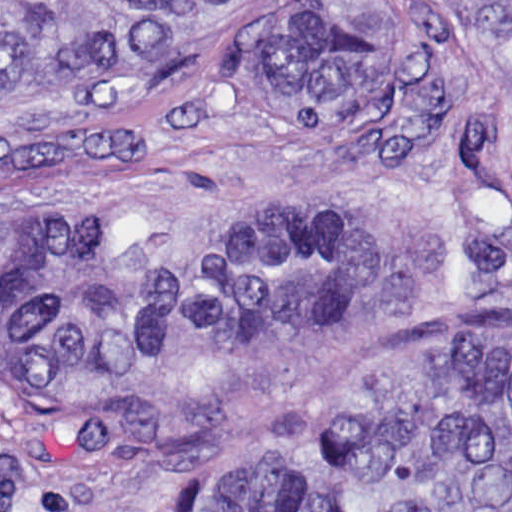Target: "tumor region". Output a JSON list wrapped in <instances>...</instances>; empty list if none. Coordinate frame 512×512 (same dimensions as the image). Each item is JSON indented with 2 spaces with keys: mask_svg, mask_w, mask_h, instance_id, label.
<instances>
[{
  "mask_svg": "<svg viewBox=\"0 0 512 512\" xmlns=\"http://www.w3.org/2000/svg\"><path fill=\"white\" fill-rule=\"evenodd\" d=\"M272 111L326 124L389 93L427 26L491 62L465 147L512 127V0H0V114L128 103L9 161L79 177L179 129L196 71L252 38ZM512 192V187H511ZM360 242L306 202H163L94 223L0 220V383L190 366L350 294ZM213 512H512V335L330 411Z\"/></svg>",
  "mask_w": 512,
  "mask_h": 512,
  "instance_id": "tumor-region-1",
  "label": "tumor region"
}]
</instances>
